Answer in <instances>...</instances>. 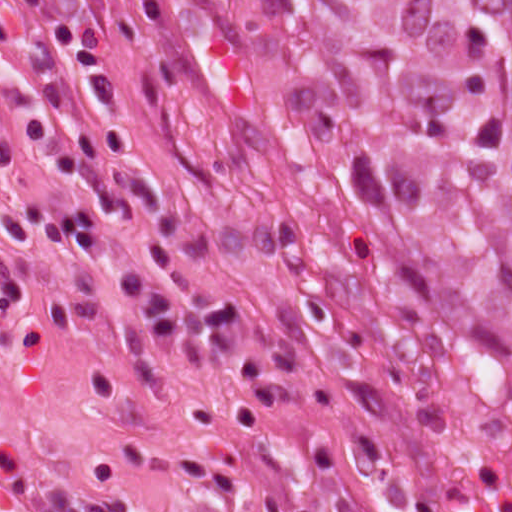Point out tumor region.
Segmentation results:
<instances>
[{"label":"tumor region","mask_w":512,"mask_h":512,"mask_svg":"<svg viewBox=\"0 0 512 512\" xmlns=\"http://www.w3.org/2000/svg\"><path fill=\"white\" fill-rule=\"evenodd\" d=\"M388 400L512 444V0H170Z\"/></svg>","instance_id":"e687c5a6"}]
</instances>
